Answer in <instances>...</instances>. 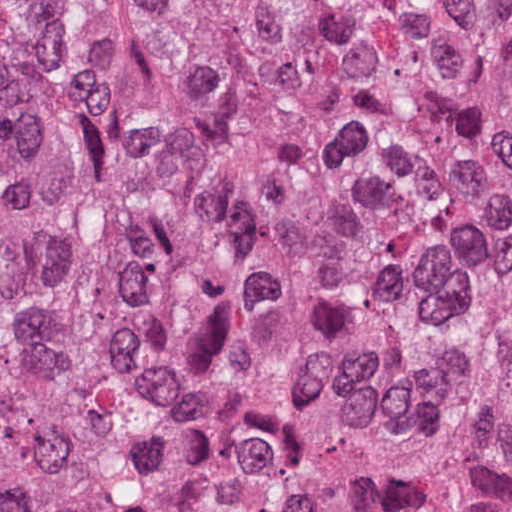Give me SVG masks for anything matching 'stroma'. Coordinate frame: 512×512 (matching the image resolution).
Segmentation results:
<instances>
[{
	"mask_svg": "<svg viewBox=\"0 0 512 512\" xmlns=\"http://www.w3.org/2000/svg\"><path fill=\"white\" fill-rule=\"evenodd\" d=\"M53 49L145 285L165 413L162 464L135 512H277L225 455L210 409V317L162 203L151 98L182 0H50Z\"/></svg>",
	"mask_w": 512,
	"mask_h": 512,
	"instance_id": "obj_1",
	"label": "stroma"
}]
</instances>
